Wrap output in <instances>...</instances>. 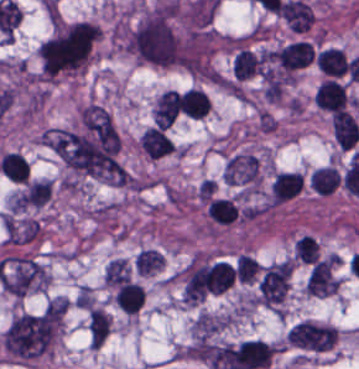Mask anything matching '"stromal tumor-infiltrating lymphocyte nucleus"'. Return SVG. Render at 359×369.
Returning <instances> with one entry per match:
<instances>
[{
  "mask_svg": "<svg viewBox=\"0 0 359 369\" xmlns=\"http://www.w3.org/2000/svg\"><path fill=\"white\" fill-rule=\"evenodd\" d=\"M202 202L210 224L216 227L236 222L241 213L238 203L232 197L213 193Z\"/></svg>",
  "mask_w": 359,
  "mask_h": 369,
  "instance_id": "obj_1",
  "label": "stromal tumor-infiltrating lymphocyte nucleus"
},
{
  "mask_svg": "<svg viewBox=\"0 0 359 369\" xmlns=\"http://www.w3.org/2000/svg\"><path fill=\"white\" fill-rule=\"evenodd\" d=\"M303 188L301 173L280 171L271 182V203L279 204L293 198Z\"/></svg>",
  "mask_w": 359,
  "mask_h": 369,
  "instance_id": "obj_2",
  "label": "stromal tumor-infiltrating lymphocyte nucleus"
},
{
  "mask_svg": "<svg viewBox=\"0 0 359 369\" xmlns=\"http://www.w3.org/2000/svg\"><path fill=\"white\" fill-rule=\"evenodd\" d=\"M143 298V289L134 281H120L114 293L119 309L127 313H135Z\"/></svg>",
  "mask_w": 359,
  "mask_h": 369,
  "instance_id": "obj_3",
  "label": "stromal tumor-infiltrating lymphocyte nucleus"
},
{
  "mask_svg": "<svg viewBox=\"0 0 359 369\" xmlns=\"http://www.w3.org/2000/svg\"><path fill=\"white\" fill-rule=\"evenodd\" d=\"M294 255L302 263H315L317 249L315 238L304 234L294 242Z\"/></svg>",
  "mask_w": 359,
  "mask_h": 369,
  "instance_id": "obj_4",
  "label": "stromal tumor-infiltrating lymphocyte nucleus"
}]
</instances>
